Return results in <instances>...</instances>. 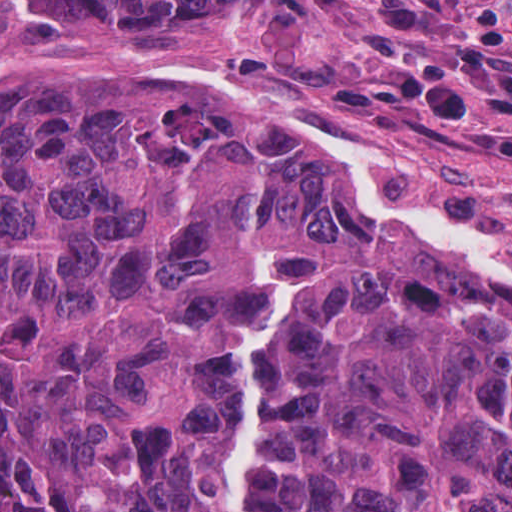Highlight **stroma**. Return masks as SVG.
<instances>
[{"label": "stroma", "mask_w": 512, "mask_h": 512, "mask_svg": "<svg viewBox=\"0 0 512 512\" xmlns=\"http://www.w3.org/2000/svg\"><path fill=\"white\" fill-rule=\"evenodd\" d=\"M224 90L318 140L374 144L400 182L512 246V0H232L104 21L0 0V73ZM358 188V187H357Z\"/></svg>", "instance_id": "stroma-1"}]
</instances>
